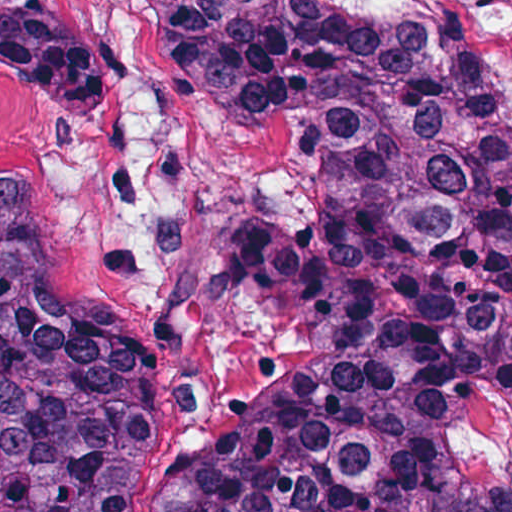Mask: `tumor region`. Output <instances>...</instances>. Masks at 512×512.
<instances>
[{
  "mask_svg": "<svg viewBox=\"0 0 512 512\" xmlns=\"http://www.w3.org/2000/svg\"><path fill=\"white\" fill-rule=\"evenodd\" d=\"M187 90L284 136L314 217L257 210L243 291L288 389L168 512H512V102L458 28L346 0H122ZM0 76L105 110L52 0H0ZM132 338L52 279L0 172V512H126Z\"/></svg>",
  "mask_w": 512,
  "mask_h": 512,
  "instance_id": "1",
  "label": "tumor region"
}]
</instances>
